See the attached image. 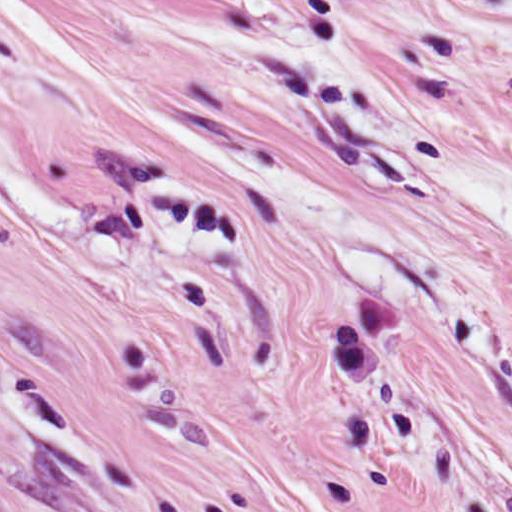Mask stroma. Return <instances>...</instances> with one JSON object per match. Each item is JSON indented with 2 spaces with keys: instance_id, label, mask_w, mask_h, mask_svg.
<instances>
[{
  "instance_id": "35a3bbf8",
  "label": "stroma",
  "mask_w": 512,
  "mask_h": 512,
  "mask_svg": "<svg viewBox=\"0 0 512 512\" xmlns=\"http://www.w3.org/2000/svg\"><path fill=\"white\" fill-rule=\"evenodd\" d=\"M0 512H512V172L0 400Z\"/></svg>"
}]
</instances>
